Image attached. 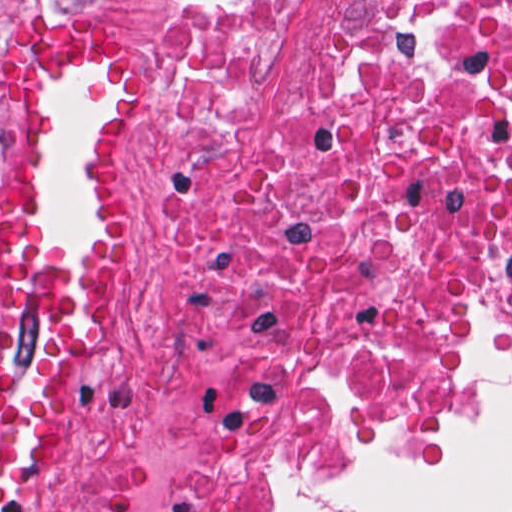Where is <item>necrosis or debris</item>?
<instances>
[{"label":"necrosis or debris","mask_w":512,"mask_h":512,"mask_svg":"<svg viewBox=\"0 0 512 512\" xmlns=\"http://www.w3.org/2000/svg\"><path fill=\"white\" fill-rule=\"evenodd\" d=\"M273 1L178 14L171 343L68 512H263L232 478L404 457L512 363V0H355L277 99Z\"/></svg>","instance_id":"obj_1"}]
</instances>
